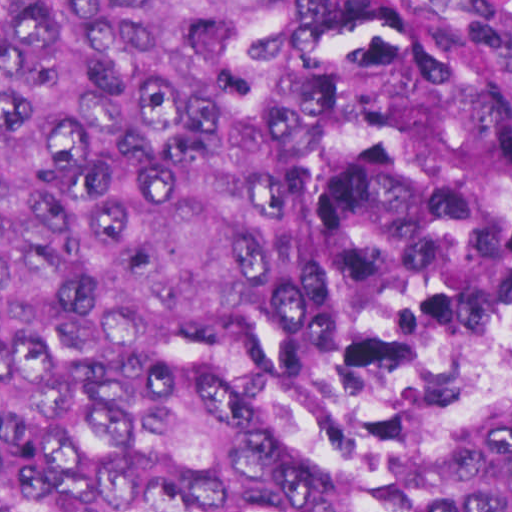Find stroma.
<instances>
[{
  "mask_svg": "<svg viewBox=\"0 0 512 512\" xmlns=\"http://www.w3.org/2000/svg\"><path fill=\"white\" fill-rule=\"evenodd\" d=\"M512 53V0H371Z\"/></svg>",
  "mask_w": 512,
  "mask_h": 512,
  "instance_id": "stroma-1",
  "label": "stroma"
}]
</instances>
